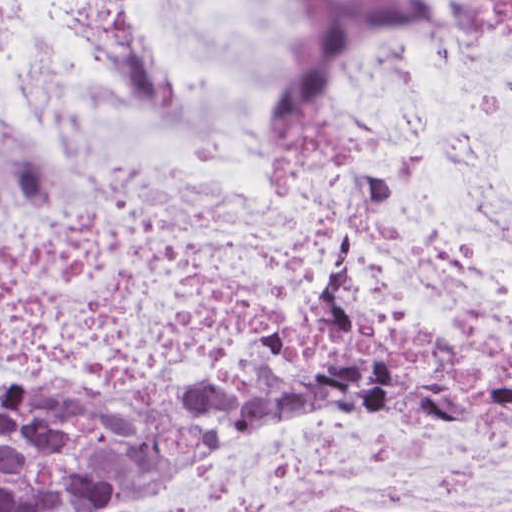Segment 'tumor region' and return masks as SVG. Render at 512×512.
Instances as JSON below:
<instances>
[{"label":"tumor region","mask_w":512,"mask_h":512,"mask_svg":"<svg viewBox=\"0 0 512 512\" xmlns=\"http://www.w3.org/2000/svg\"><path fill=\"white\" fill-rule=\"evenodd\" d=\"M265 394L385 405L469 436H512V359L402 328L361 272L195 401L59 403L1 377V512H74L209 445Z\"/></svg>","instance_id":"tumor-region-1"}]
</instances>
